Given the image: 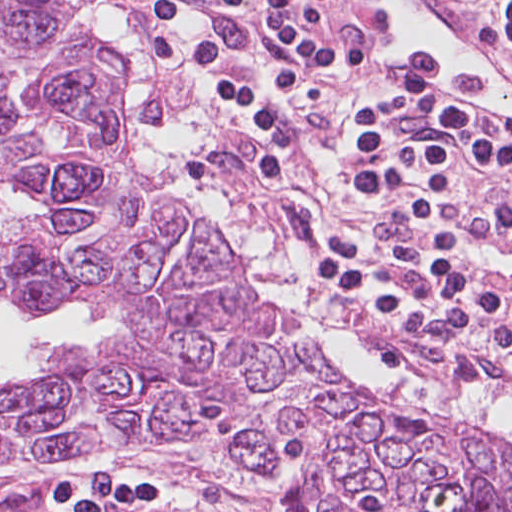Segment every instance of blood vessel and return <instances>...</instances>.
<instances>
[{
    "label": "blood vessel",
    "instance_id": "1",
    "mask_svg": "<svg viewBox=\"0 0 512 512\" xmlns=\"http://www.w3.org/2000/svg\"><path fill=\"white\" fill-rule=\"evenodd\" d=\"M354 75L453 109L480 134L512 142V54L445 0H358Z\"/></svg>",
    "mask_w": 512,
    "mask_h": 512
}]
</instances>
